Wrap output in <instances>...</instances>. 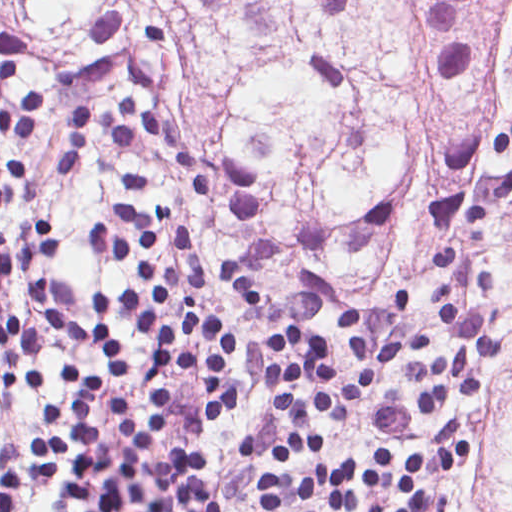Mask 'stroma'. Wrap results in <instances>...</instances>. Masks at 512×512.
<instances>
[{
  "instance_id": "35a3bbf8",
  "label": "stroma",
  "mask_w": 512,
  "mask_h": 512,
  "mask_svg": "<svg viewBox=\"0 0 512 512\" xmlns=\"http://www.w3.org/2000/svg\"><path fill=\"white\" fill-rule=\"evenodd\" d=\"M25 40L19 77L9 92L43 94L38 124L29 134H0V158L19 159L35 184V198L0 209V227L40 223L53 232V255L25 271H11L0 291V316L18 315L42 336V383L12 393L4 383L0 346V471L21 473V512H71L64 498L80 462L68 423L71 389L78 376L103 380L87 407L90 428L108 448L118 441L109 413L112 392L133 394L142 426L156 422V398L165 388L167 422L149 456L169 451L172 442H193L206 455L203 481L222 512L246 505L258 511L257 488L274 476L271 459L282 428L270 382V357L264 338L270 330L302 326L331 347L340 374H357L341 327V312L362 316L372 360L391 340L413 328H428L434 347L402 349L377 387L354 414L339 422L326 412L315 417L311 434L323 451L299 459L284 472L299 482L306 472H331L352 458L370 471L372 450L393 454V465L371 491H359L368 507H408L402 488L403 465L410 452L426 462L418 484L430 493L428 512H448L449 497L481 470L485 458L484 424L501 398V370L511 354L512 338L498 299L512 296V219L504 202L466 220L435 225L419 235L411 253V285L403 298L388 296L366 274L294 277L271 291H242L231 282L229 251L240 227V189L234 164L215 146L203 114L185 83L175 80H115L105 86L59 83L49 72L46 37L40 24L16 7H0V33ZM128 90L142 105L185 129L212 172V197H198L183 172L148 133L134 147L112 145L101 129L90 133L82 164L59 175V132L64 112L78 100L103 106ZM110 207L170 215L181 227L194 263L203 274L198 301L216 316L234 323L243 343L242 359L232 374L242 397L240 411L226 425L202 422L197 407L207 384L183 370L156 378L164 366L161 350L147 336L118 331L113 345L134 365L124 378L92 350V308L97 287H126L138 280L94 247L89 233L112 221ZM444 245H465L480 272L499 287L477 289V299L495 306L493 328L501 347L485 358V384L475 400H448L429 414L415 412L420 381L409 364L446 357L452 348L436 284L420 265ZM40 432V433H39ZM39 433V434H38ZM38 434L63 440V469L51 484L37 479L31 440Z\"/></svg>"
}]
</instances>
